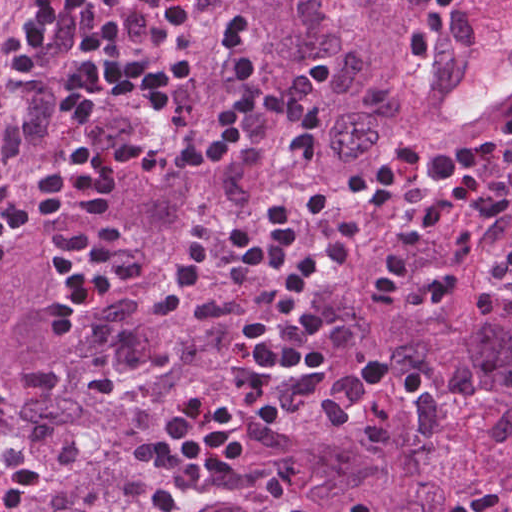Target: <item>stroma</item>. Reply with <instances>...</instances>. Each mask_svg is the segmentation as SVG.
Segmentation results:
<instances>
[{"label":"stroma","instance_id":"35a3bbf8","mask_svg":"<svg viewBox=\"0 0 512 512\" xmlns=\"http://www.w3.org/2000/svg\"><path fill=\"white\" fill-rule=\"evenodd\" d=\"M50 1L51 0H26L22 8H17V10L24 21H31L39 10H46ZM192 1L193 0H185L183 12ZM425 1L426 0L417 6L419 17ZM158 6L159 0H118L117 12L122 25L137 31L150 28L156 16ZM133 51L143 59L155 63L157 62L160 52V50L150 45L128 43L121 44L112 52L97 59L83 55L80 44L78 8V27L64 54L57 60L80 68L97 70L116 58ZM408 57L418 71L422 72L424 75L429 74V68H426L414 61L411 49ZM511 110L504 113L490 125L475 133L467 140L452 146L431 145L423 135L427 120L424 119L417 122L408 131L397 135L392 140L381 143L366 151L350 163L345 176L338 185L334 194L330 197L332 198L337 211L330 222L342 220L344 210L342 194L344 193L353 173L363 162L367 161L371 157L388 153H394L404 157L418 156L434 151L451 149L462 144L476 147H497L503 136L505 117ZM181 113L182 107L180 101L168 115L157 121L145 118L135 113L136 132L133 136L155 141L169 139L179 134ZM131 183H153L163 188L167 195L169 201V226L160 251L170 241L180 237L191 236L202 226L220 227L234 223L251 209L275 200L300 196L287 185L276 190L273 194L257 201L244 213H240L234 208L232 203L227 205H210L200 200L182 184L170 183L154 175L142 172L126 174L122 184ZM476 199L477 197L470 189L441 188L435 194H432L416 204L387 206L376 212L367 223L368 238L375 232L395 223L409 213L422 209L444 206H450L455 209L462 207L473 210ZM477 225L480 229L477 250L478 274L484 286L492 296L505 308L512 310V275L509 276L500 268L498 257V253L509 241L512 240V218L496 219L479 223ZM161 255L162 253L159 254L157 260H159ZM332 285L324 290L320 296L325 295Z\"/></svg>","mask_w":512,"mask_h":512}]
</instances>
